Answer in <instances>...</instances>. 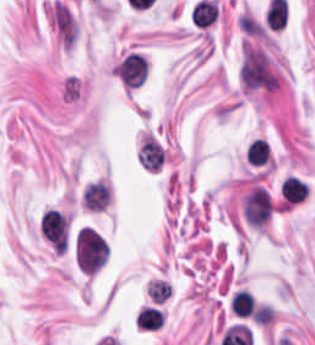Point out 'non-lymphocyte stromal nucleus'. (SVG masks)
Instances as JSON below:
<instances>
[{"instance_id":"obj_1","label":"non-lymphocyte stromal nucleus","mask_w":315,"mask_h":345,"mask_svg":"<svg viewBox=\"0 0 315 345\" xmlns=\"http://www.w3.org/2000/svg\"><path fill=\"white\" fill-rule=\"evenodd\" d=\"M241 82L246 90H272L275 74L264 52L245 42L240 66Z\"/></svg>"},{"instance_id":"obj_2","label":"non-lymphocyte stromal nucleus","mask_w":315,"mask_h":345,"mask_svg":"<svg viewBox=\"0 0 315 345\" xmlns=\"http://www.w3.org/2000/svg\"><path fill=\"white\" fill-rule=\"evenodd\" d=\"M51 18L63 44L70 47L75 42L76 24L67 6L57 0L53 5Z\"/></svg>"}]
</instances>
